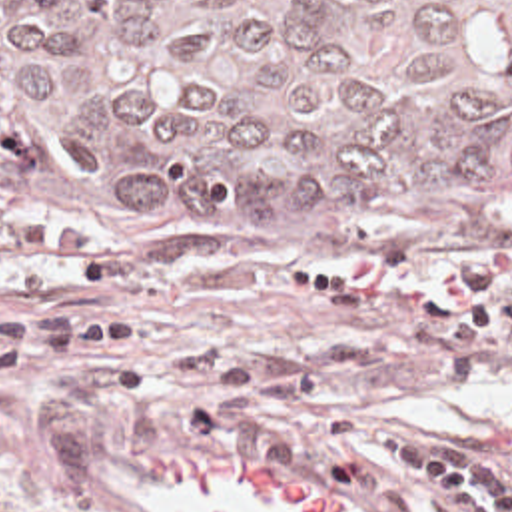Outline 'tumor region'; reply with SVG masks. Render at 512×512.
<instances>
[{
    "label": "tumor region",
    "instance_id": "obj_1",
    "mask_svg": "<svg viewBox=\"0 0 512 512\" xmlns=\"http://www.w3.org/2000/svg\"><path fill=\"white\" fill-rule=\"evenodd\" d=\"M0 184L498 250L512 0H0Z\"/></svg>",
    "mask_w": 512,
    "mask_h": 512
}]
</instances>
